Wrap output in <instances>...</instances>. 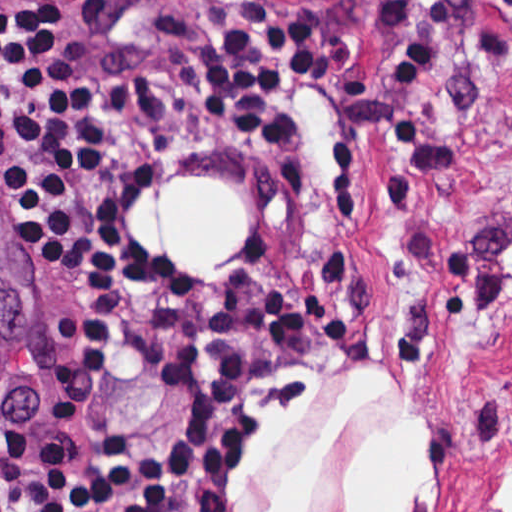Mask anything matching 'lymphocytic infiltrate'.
I'll return each instance as SVG.
<instances>
[{
  "label": "lymphocytic infiltrate",
  "mask_w": 512,
  "mask_h": 512,
  "mask_svg": "<svg viewBox=\"0 0 512 512\" xmlns=\"http://www.w3.org/2000/svg\"><path fill=\"white\" fill-rule=\"evenodd\" d=\"M333 67L290 10L246 3L182 84L233 146L302 169L314 127L297 93ZM119 164L93 129L65 1L0 0L3 195L30 251L80 288L42 416L0 427V512H213L248 381L295 323L297 293L186 288L127 235Z\"/></svg>",
  "instance_id": "obj_1"
}]
</instances>
